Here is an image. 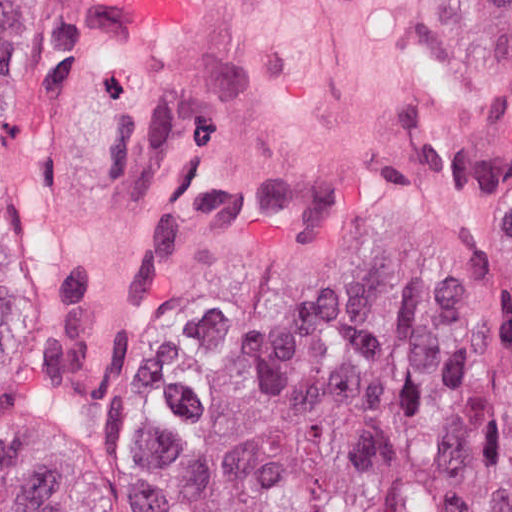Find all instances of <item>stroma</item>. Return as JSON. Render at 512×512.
I'll return each mask as SVG.
<instances>
[{
	"label": "stroma",
	"mask_w": 512,
	"mask_h": 512,
	"mask_svg": "<svg viewBox=\"0 0 512 512\" xmlns=\"http://www.w3.org/2000/svg\"><path fill=\"white\" fill-rule=\"evenodd\" d=\"M3 112L50 512H183L212 388L372 276L512 316V0H29Z\"/></svg>",
	"instance_id": "1"
}]
</instances>
